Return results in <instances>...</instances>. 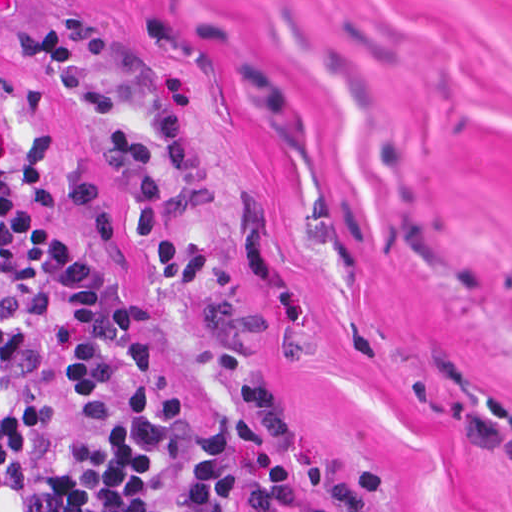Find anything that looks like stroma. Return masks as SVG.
Instances as JSON below:
<instances>
[{"instance_id":"35a3bbf8","label":"stroma","mask_w":512,"mask_h":512,"mask_svg":"<svg viewBox=\"0 0 512 512\" xmlns=\"http://www.w3.org/2000/svg\"><path fill=\"white\" fill-rule=\"evenodd\" d=\"M0 127L267 512H512V0H0Z\"/></svg>"}]
</instances>
